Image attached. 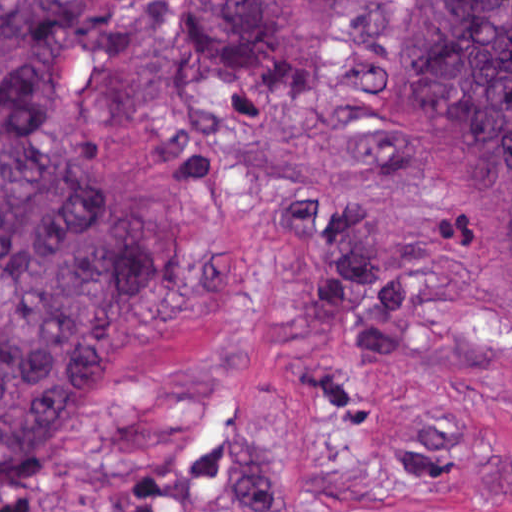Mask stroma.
Instances as JSON below:
<instances>
[{
  "mask_svg": "<svg viewBox=\"0 0 512 512\" xmlns=\"http://www.w3.org/2000/svg\"><path fill=\"white\" fill-rule=\"evenodd\" d=\"M328 38L301 104L234 106L174 77L152 0H89L40 87L47 138L144 185L180 277L77 383L17 512H118L130 479L209 490L252 465L269 512H512V288L413 180L367 90L384 0H295ZM308 178L390 234L405 360L355 368L309 330L270 181Z\"/></svg>",
  "mask_w": 512,
  "mask_h": 512,
  "instance_id": "35a3bbf8",
  "label": "stroma"
}]
</instances>
